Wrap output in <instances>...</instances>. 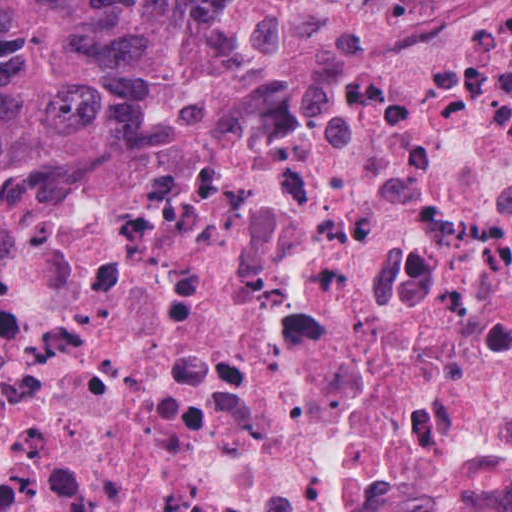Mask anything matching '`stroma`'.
Returning a JSON list of instances; mask_svg holds the SVG:
<instances>
[{"label":"stroma","instance_id":"1","mask_svg":"<svg viewBox=\"0 0 512 512\" xmlns=\"http://www.w3.org/2000/svg\"><path fill=\"white\" fill-rule=\"evenodd\" d=\"M274 24V23H273ZM272 24V25H273ZM271 25V26H272ZM140 128L109 127L75 150L44 197L77 175L86 158L119 142ZM43 197V198H44ZM42 198V199H43ZM41 199V200H42ZM405 512H469V511H405Z\"/></svg>","mask_w":512,"mask_h":512}]
</instances>
